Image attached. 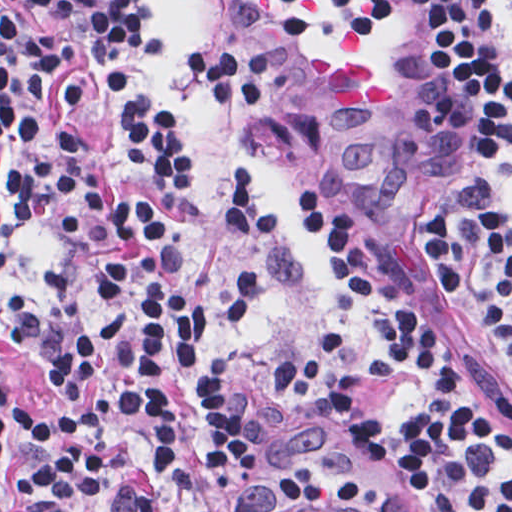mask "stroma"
<instances>
[{"mask_svg":"<svg viewBox=\"0 0 512 512\" xmlns=\"http://www.w3.org/2000/svg\"><path fill=\"white\" fill-rule=\"evenodd\" d=\"M249 0H137L145 26L134 82L176 124L183 174L163 194L136 164L117 106L88 108V158L104 181L151 197L182 249L193 294L207 313L235 281V241L223 192L242 166L259 171L282 218L277 281L250 332L228 347L244 428L262 454L248 482L214 512H300L277 476L324 512H436L413 481L376 454L334 411L287 391L271 357L306 345L338 316L370 330L360 293L302 219L282 183L337 201L358 242L396 274L411 232L451 180L454 114L442 92L438 50L415 21L273 29L255 25ZM503 50V200L512 219V0H485ZM16 20L54 29L58 18L30 0H0ZM196 41L216 43L273 92L268 104L213 98ZM20 156L0 145V168ZM8 199L0 197V217ZM0 282L21 292L68 285L51 225L22 219L0 231ZM439 327L455 370L512 424V361L459 287L435 283ZM13 380H38L0 352ZM420 399L416 374L376 377L358 401L380 422L400 424ZM452 512H468L452 505Z\"/></svg>","mask_w":512,"mask_h":512,"instance_id":"obj_1","label":"stroma"}]
</instances>
